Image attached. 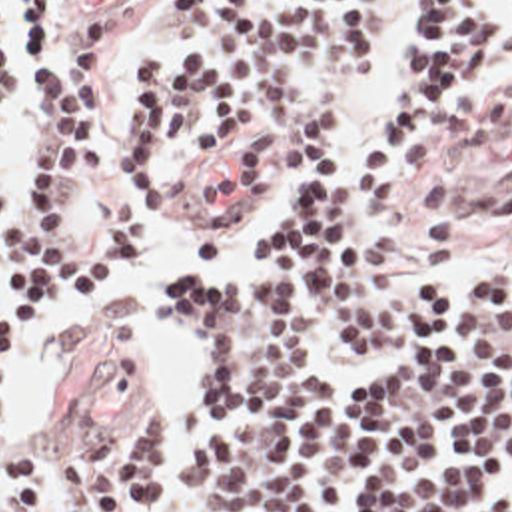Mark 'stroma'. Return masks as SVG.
I'll use <instances>...</instances> for the list:
<instances>
[{
	"instance_id": "obj_1",
	"label": "stroma",
	"mask_w": 512,
	"mask_h": 512,
	"mask_svg": "<svg viewBox=\"0 0 512 512\" xmlns=\"http://www.w3.org/2000/svg\"><path fill=\"white\" fill-rule=\"evenodd\" d=\"M500 1V0H484ZM414 0H390L386 35L375 69L345 107V135L331 167H343L361 153L376 99L394 67L396 51ZM165 0H127L113 25V93L117 103V167L111 183L97 195L83 191V227L101 231L115 207V185L121 163V137L135 119L131 67L149 55H189V43L163 27ZM63 23L57 0V27L49 51L63 67ZM35 75L23 77L21 11L15 9V87L0 133V189L11 201L17 181L33 155ZM269 199L257 201L241 193L227 165L207 159L197 181L165 201L159 213L141 217V243L105 291L91 303L75 305L57 299L41 329H17V361L0 385V407L15 387L21 357L39 345L49 323L81 319L119 297L133 271L143 263L147 241L161 231L181 233L205 243L219 231H239L235 259L199 261L177 269L159 285V327L185 367L187 399L169 423V476L175 460L191 440L195 401L199 397V359L193 339L173 321L163 301V283L183 275H237L261 263L259 221ZM392 241L386 273L412 283L446 277L452 285H482L512 265V73L476 87L450 103L420 133L378 201L371 237ZM149 411L157 401L147 389L143 367L125 339L101 335L81 343L63 393L37 432L15 444H0V512H23L11 490L3 462L11 452L37 450L59 458L87 434L117 425ZM47 512H83L63 486ZM163 512H201L197 502L171 492Z\"/></svg>"
}]
</instances>
